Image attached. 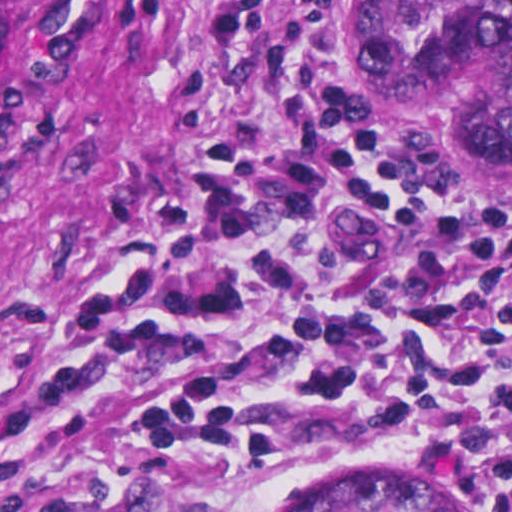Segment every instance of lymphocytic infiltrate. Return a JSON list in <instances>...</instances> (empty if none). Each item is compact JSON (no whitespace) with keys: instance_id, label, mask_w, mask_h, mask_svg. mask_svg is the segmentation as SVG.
Masks as SVG:
<instances>
[{"instance_id":"f902f5d3","label":"lymphocytic infiltrate","mask_w":512,"mask_h":512,"mask_svg":"<svg viewBox=\"0 0 512 512\" xmlns=\"http://www.w3.org/2000/svg\"><path fill=\"white\" fill-rule=\"evenodd\" d=\"M267 15L216 3L209 75ZM273 72L294 134L209 138L182 182L87 237L0 377V425L157 377L125 425L148 488L128 512H243L385 439L512 512V226L376 147L338 0L286 12Z\"/></svg>"}]
</instances>
